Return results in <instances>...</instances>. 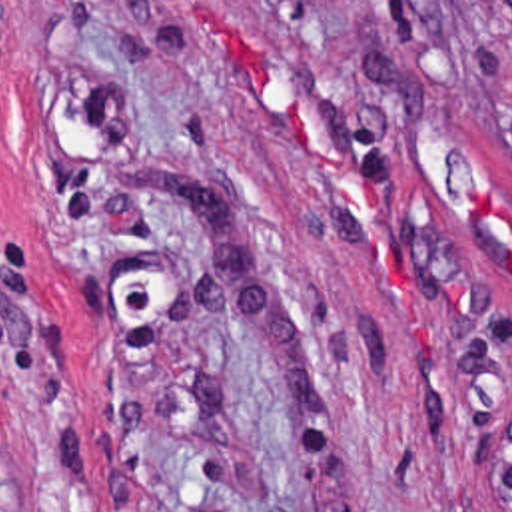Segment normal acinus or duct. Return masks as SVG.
Wrapping results in <instances>:
<instances>
[{
	"label": "normal acinus or duct",
	"instance_id": "1",
	"mask_svg": "<svg viewBox=\"0 0 512 512\" xmlns=\"http://www.w3.org/2000/svg\"><path fill=\"white\" fill-rule=\"evenodd\" d=\"M484 507L486 512H512V411L492 425Z\"/></svg>",
	"mask_w": 512,
	"mask_h": 512
}]
</instances>
